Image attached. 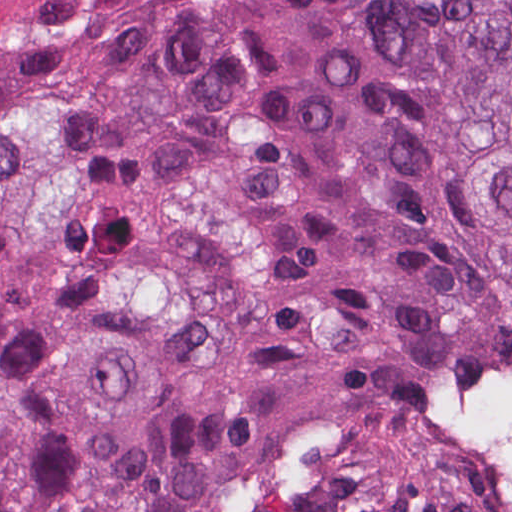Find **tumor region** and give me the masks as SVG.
Here are the masks:
<instances>
[{"mask_svg": "<svg viewBox=\"0 0 512 512\" xmlns=\"http://www.w3.org/2000/svg\"><path fill=\"white\" fill-rule=\"evenodd\" d=\"M512 361V0H0V512H466Z\"/></svg>", "mask_w": 512, "mask_h": 512, "instance_id": "1", "label": "tumor region"}]
</instances>
